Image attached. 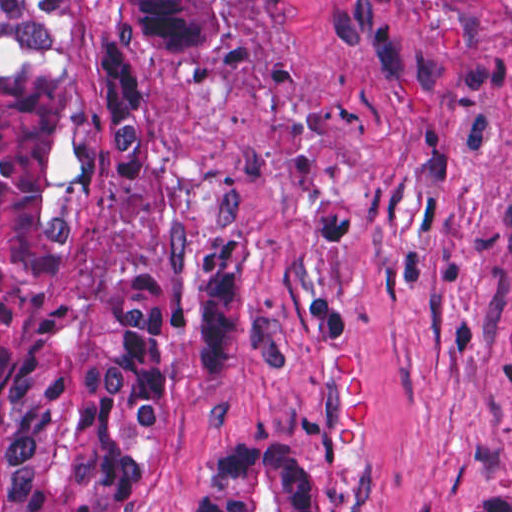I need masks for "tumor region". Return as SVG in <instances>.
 <instances>
[{"label": "tumor region", "instance_id": "e687c5a6", "mask_svg": "<svg viewBox=\"0 0 512 512\" xmlns=\"http://www.w3.org/2000/svg\"><path fill=\"white\" fill-rule=\"evenodd\" d=\"M246 1L1 0V512H141L173 407L253 353L237 257L115 273L88 255L97 179L142 141L139 73L218 56ZM185 512L323 510L302 448L245 431L185 463ZM449 512H512V489Z\"/></svg>", "mask_w": 512, "mask_h": 512}]
</instances>
